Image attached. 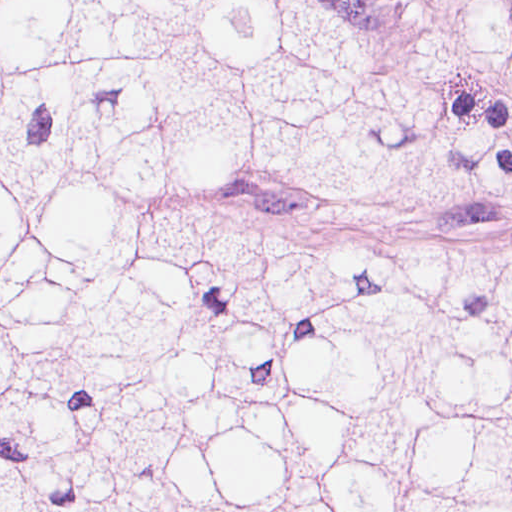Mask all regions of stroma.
<instances>
[{
  "mask_svg": "<svg viewBox=\"0 0 512 512\" xmlns=\"http://www.w3.org/2000/svg\"><path fill=\"white\" fill-rule=\"evenodd\" d=\"M382 34L415 73L440 88L461 127L512 124V57L456 33L431 0H325ZM156 199L205 202L225 213L383 237H485L512 243V205H402L332 184L217 187Z\"/></svg>",
  "mask_w": 512,
  "mask_h": 512,
  "instance_id": "35a3bbf8",
  "label": "stroma"
}]
</instances>
